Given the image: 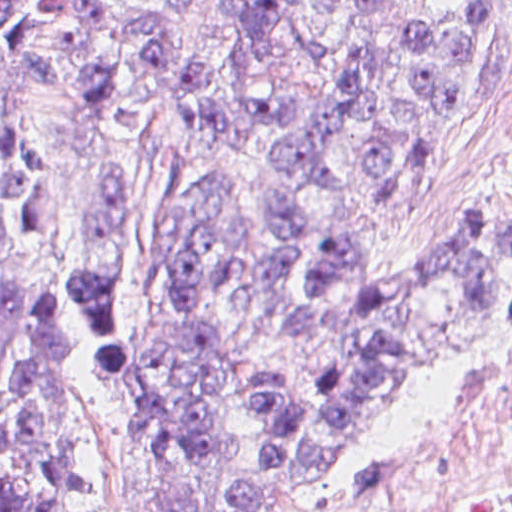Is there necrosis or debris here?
Segmentation results:
<instances>
[{
  "label": "necrosis or debris",
  "instance_id": "4bbe7bcc",
  "mask_svg": "<svg viewBox=\"0 0 512 512\" xmlns=\"http://www.w3.org/2000/svg\"><path fill=\"white\" fill-rule=\"evenodd\" d=\"M380 512H512V366L449 415Z\"/></svg>",
  "mask_w": 512,
  "mask_h": 512
}]
</instances>
